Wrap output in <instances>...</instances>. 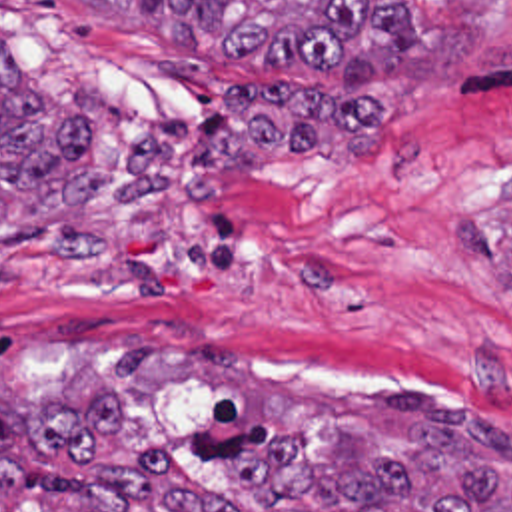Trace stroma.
<instances>
[{
    "instance_id": "stroma-1",
    "label": "stroma",
    "mask_w": 512,
    "mask_h": 512,
    "mask_svg": "<svg viewBox=\"0 0 512 512\" xmlns=\"http://www.w3.org/2000/svg\"><path fill=\"white\" fill-rule=\"evenodd\" d=\"M411 64L340 84L214 58L94 0H0V44L94 128L100 250L0 248V509L162 445L240 512L264 445L413 435L377 393L512 427V0H401ZM493 421V419H491Z\"/></svg>"
}]
</instances>
